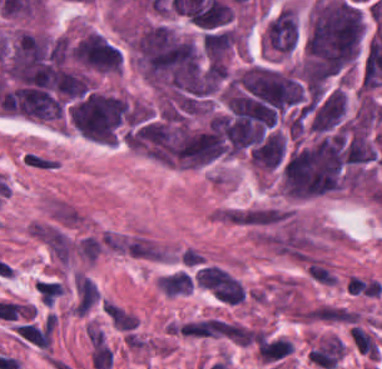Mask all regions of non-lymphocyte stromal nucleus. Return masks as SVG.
<instances>
[{
	"label": "non-lymphocyte stromal nucleus",
	"mask_w": 382,
	"mask_h": 369,
	"mask_svg": "<svg viewBox=\"0 0 382 369\" xmlns=\"http://www.w3.org/2000/svg\"><path fill=\"white\" fill-rule=\"evenodd\" d=\"M95 293L94 281L76 273L74 276L75 311L85 313L94 302Z\"/></svg>",
	"instance_id": "non-lymphocyte-stromal-nucleus-1"
},
{
	"label": "non-lymphocyte stromal nucleus",
	"mask_w": 382,
	"mask_h": 369,
	"mask_svg": "<svg viewBox=\"0 0 382 369\" xmlns=\"http://www.w3.org/2000/svg\"><path fill=\"white\" fill-rule=\"evenodd\" d=\"M90 359L94 369H108L112 355L102 336L97 331L89 333Z\"/></svg>",
	"instance_id": "non-lymphocyte-stromal-nucleus-2"
}]
</instances>
